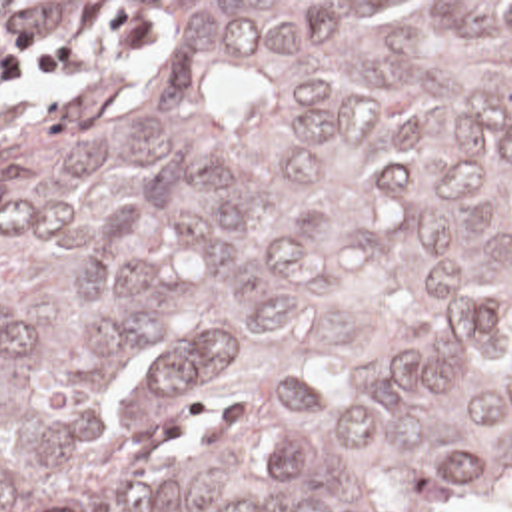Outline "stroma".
Segmentation results:
<instances>
[{"label":"stroma","mask_w":512,"mask_h":512,"mask_svg":"<svg viewBox=\"0 0 512 512\" xmlns=\"http://www.w3.org/2000/svg\"><path fill=\"white\" fill-rule=\"evenodd\" d=\"M0 2H512V0H0ZM158 46L152 22L136 14L98 16L84 28L0 62V144L64 122L104 72L134 76Z\"/></svg>","instance_id":"obj_1"}]
</instances>
